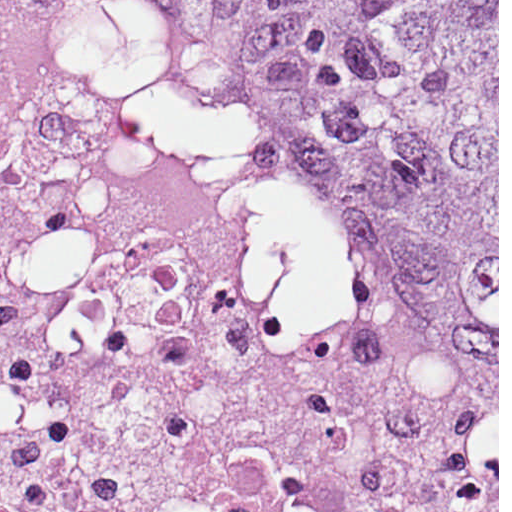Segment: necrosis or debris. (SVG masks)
Masks as SVG:
<instances>
[{"mask_svg":"<svg viewBox=\"0 0 512 512\" xmlns=\"http://www.w3.org/2000/svg\"><path fill=\"white\" fill-rule=\"evenodd\" d=\"M0 512H497L309 287L152 0H0Z\"/></svg>","mask_w":512,"mask_h":512,"instance_id":"1","label":"necrosis or debris"}]
</instances>
